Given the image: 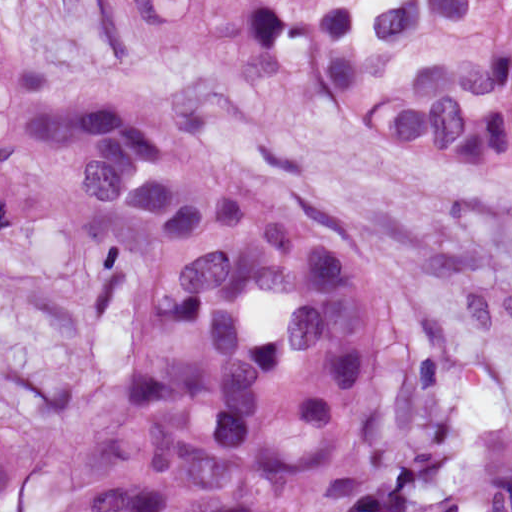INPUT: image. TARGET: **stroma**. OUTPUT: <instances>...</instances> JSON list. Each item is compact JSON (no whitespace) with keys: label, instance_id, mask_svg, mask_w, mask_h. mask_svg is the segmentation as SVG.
Listing matches in <instances>:
<instances>
[{"label":"stroma","instance_id":"35a3bbf8","mask_svg":"<svg viewBox=\"0 0 512 512\" xmlns=\"http://www.w3.org/2000/svg\"><path fill=\"white\" fill-rule=\"evenodd\" d=\"M20 30L119 103L138 94L85 0H0ZM190 139L337 237L391 310L410 455L446 486L512 420V201L408 149L301 110ZM122 356L101 303L0 266V440L24 487L0 505L60 512L97 457Z\"/></svg>","mask_w":512,"mask_h":512}]
</instances>
